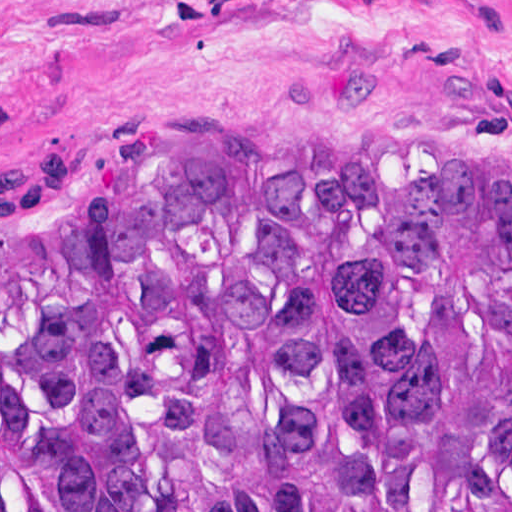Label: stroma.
<instances>
[{
    "instance_id": "1",
    "label": "stroma",
    "mask_w": 512,
    "mask_h": 512,
    "mask_svg": "<svg viewBox=\"0 0 512 512\" xmlns=\"http://www.w3.org/2000/svg\"><path fill=\"white\" fill-rule=\"evenodd\" d=\"M32 174H512V0H0Z\"/></svg>"
}]
</instances>
